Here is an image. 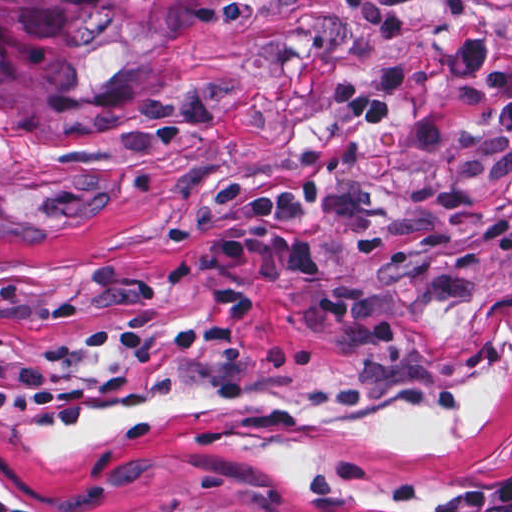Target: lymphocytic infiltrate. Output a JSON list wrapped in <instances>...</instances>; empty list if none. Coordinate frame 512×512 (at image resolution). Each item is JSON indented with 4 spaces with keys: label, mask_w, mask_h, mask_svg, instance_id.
Masks as SVG:
<instances>
[{
    "label": "lymphocytic infiltrate",
    "mask_w": 512,
    "mask_h": 512,
    "mask_svg": "<svg viewBox=\"0 0 512 512\" xmlns=\"http://www.w3.org/2000/svg\"><path fill=\"white\" fill-rule=\"evenodd\" d=\"M452 63L468 86L488 96L495 125L512 136V49L469 34L455 45ZM336 86L335 110L346 125L392 126L410 90V65L395 53H372L366 59V87L357 89L352 78ZM321 206L320 184L305 190L259 189L244 206L249 236L294 280L322 277L323 261L310 235ZM96 512L270 511L245 500L209 493H147L113 500ZM450 512H512V477Z\"/></svg>",
    "instance_id": "obj_1"
}]
</instances>
